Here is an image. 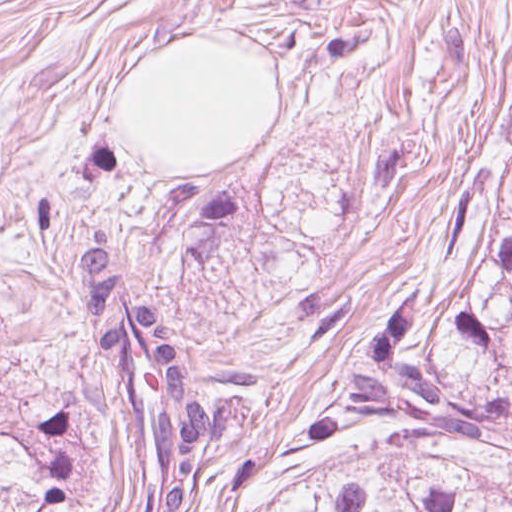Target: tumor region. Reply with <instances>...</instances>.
Here are the masks:
<instances>
[{"instance_id":"e687c5a6","label":"tumor region","mask_w":512,"mask_h":512,"mask_svg":"<svg viewBox=\"0 0 512 512\" xmlns=\"http://www.w3.org/2000/svg\"><path fill=\"white\" fill-rule=\"evenodd\" d=\"M91 347L129 421L127 512H196L206 458L244 438L256 369L206 365L131 282L107 227L73 244ZM67 475V403L0 387V512ZM230 512H512V95L471 164L433 275L288 448H252Z\"/></svg>"}]
</instances>
